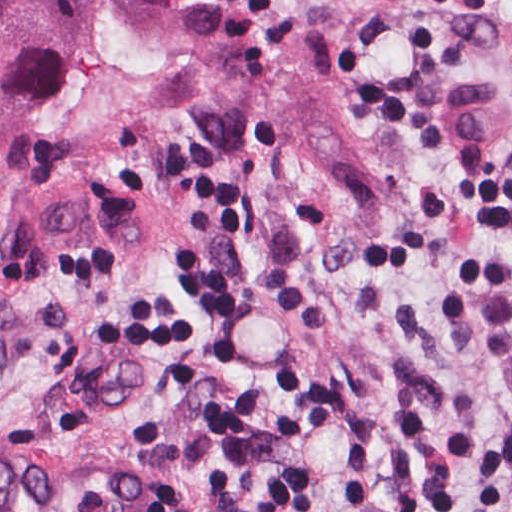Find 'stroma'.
Masks as SVG:
<instances>
[{"label": "stroma", "instance_id": "obj_1", "mask_svg": "<svg viewBox=\"0 0 512 512\" xmlns=\"http://www.w3.org/2000/svg\"><path fill=\"white\" fill-rule=\"evenodd\" d=\"M29 115L2 234L50 180L113 185L140 248L0 268V453L156 482L158 512H512V0H400L360 178L216 107L186 41Z\"/></svg>", "mask_w": 512, "mask_h": 512}]
</instances>
